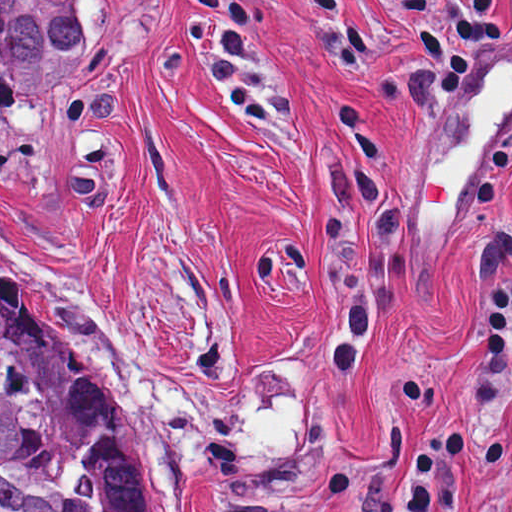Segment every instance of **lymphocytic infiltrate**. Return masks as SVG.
Masks as SVG:
<instances>
[{"instance_id":"1","label":"lymphocytic infiltrate","mask_w":512,"mask_h":512,"mask_svg":"<svg viewBox=\"0 0 512 512\" xmlns=\"http://www.w3.org/2000/svg\"><path fill=\"white\" fill-rule=\"evenodd\" d=\"M512 370V270L495 282L484 321V393ZM484 471L499 512H512V438L484 439Z\"/></svg>"}]
</instances>
